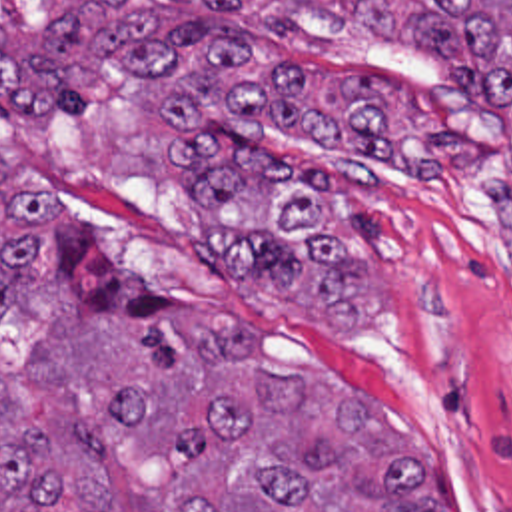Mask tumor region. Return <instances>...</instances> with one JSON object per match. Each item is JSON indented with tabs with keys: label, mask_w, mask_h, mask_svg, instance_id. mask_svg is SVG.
Here are the masks:
<instances>
[{
	"label": "tumor region",
	"mask_w": 512,
	"mask_h": 512,
	"mask_svg": "<svg viewBox=\"0 0 512 512\" xmlns=\"http://www.w3.org/2000/svg\"><path fill=\"white\" fill-rule=\"evenodd\" d=\"M288 1L395 41L364 85H336L266 55L240 0H0V113L76 111L98 77L136 79L150 101V209L300 323L352 329L371 313L352 205L360 153L429 161L483 137L512 227V0ZM266 129L320 141L298 177L250 153ZM0 157L52 199L64 297L130 341L54 303L0 189V512H455L364 391L258 339L188 345L176 311L244 317L168 293L100 245L2 131ZM371 426L407 444L429 502Z\"/></svg>",
	"instance_id": "e687c5a6"
}]
</instances>
